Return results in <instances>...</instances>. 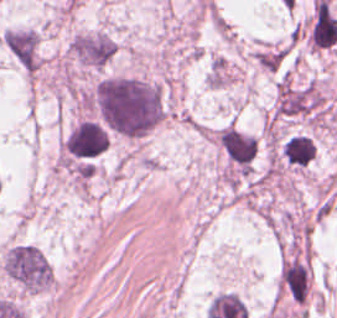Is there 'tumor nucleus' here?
Instances as JSON below:
<instances>
[{
	"label": "tumor nucleus",
	"mask_w": 337,
	"mask_h": 318,
	"mask_svg": "<svg viewBox=\"0 0 337 318\" xmlns=\"http://www.w3.org/2000/svg\"><path fill=\"white\" fill-rule=\"evenodd\" d=\"M316 143L312 136L290 133L280 143V156L286 168L303 169L315 156Z\"/></svg>",
	"instance_id": "obj_4"
},
{
	"label": "tumor nucleus",
	"mask_w": 337,
	"mask_h": 318,
	"mask_svg": "<svg viewBox=\"0 0 337 318\" xmlns=\"http://www.w3.org/2000/svg\"><path fill=\"white\" fill-rule=\"evenodd\" d=\"M116 51L114 40L103 31H83L68 42L67 57L82 71L106 66Z\"/></svg>",
	"instance_id": "obj_3"
},
{
	"label": "tumor nucleus",
	"mask_w": 337,
	"mask_h": 318,
	"mask_svg": "<svg viewBox=\"0 0 337 318\" xmlns=\"http://www.w3.org/2000/svg\"><path fill=\"white\" fill-rule=\"evenodd\" d=\"M0 266L20 292L32 293L50 285L52 268L42 249L32 243L12 242L6 248Z\"/></svg>",
	"instance_id": "obj_2"
},
{
	"label": "tumor nucleus",
	"mask_w": 337,
	"mask_h": 318,
	"mask_svg": "<svg viewBox=\"0 0 337 318\" xmlns=\"http://www.w3.org/2000/svg\"><path fill=\"white\" fill-rule=\"evenodd\" d=\"M106 132L129 138L146 134L162 117L157 82L129 74H103L86 96Z\"/></svg>",
	"instance_id": "obj_1"
}]
</instances>
